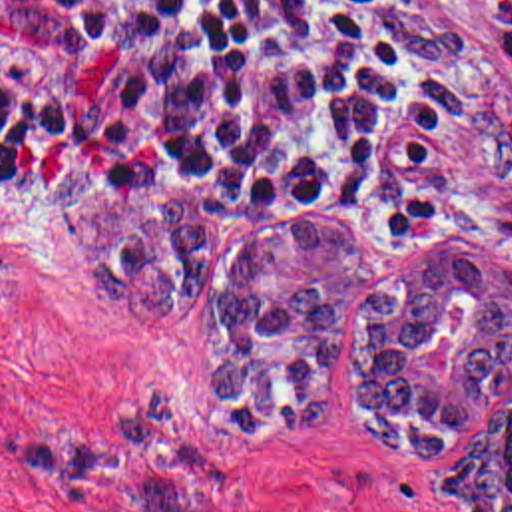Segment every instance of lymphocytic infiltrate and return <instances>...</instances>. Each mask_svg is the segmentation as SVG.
I'll return each instance as SVG.
<instances>
[{"label": "lymphocytic infiltrate", "mask_w": 512, "mask_h": 512, "mask_svg": "<svg viewBox=\"0 0 512 512\" xmlns=\"http://www.w3.org/2000/svg\"><path fill=\"white\" fill-rule=\"evenodd\" d=\"M444 125L392 0H0V171L75 141L105 173L364 213Z\"/></svg>", "instance_id": "f902f5d3"}]
</instances>
